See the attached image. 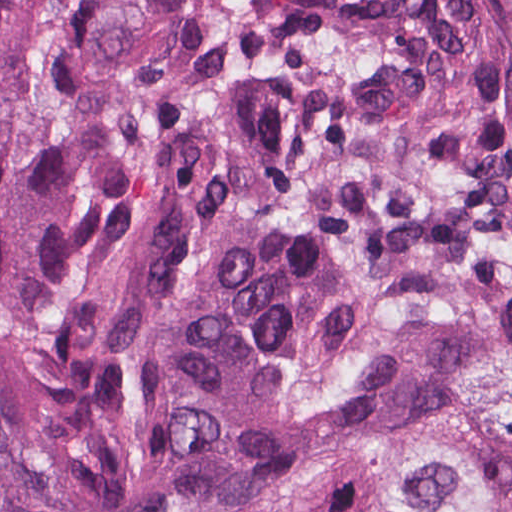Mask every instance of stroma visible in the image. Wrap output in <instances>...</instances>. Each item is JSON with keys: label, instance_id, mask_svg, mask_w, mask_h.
Instances as JSON below:
<instances>
[{"label": "stroma", "instance_id": "stroma-1", "mask_svg": "<svg viewBox=\"0 0 512 512\" xmlns=\"http://www.w3.org/2000/svg\"><path fill=\"white\" fill-rule=\"evenodd\" d=\"M473 13L512 43V0H466ZM354 472L332 482L283 500L261 512L296 507H318L342 495Z\"/></svg>", "mask_w": 512, "mask_h": 512}]
</instances>
